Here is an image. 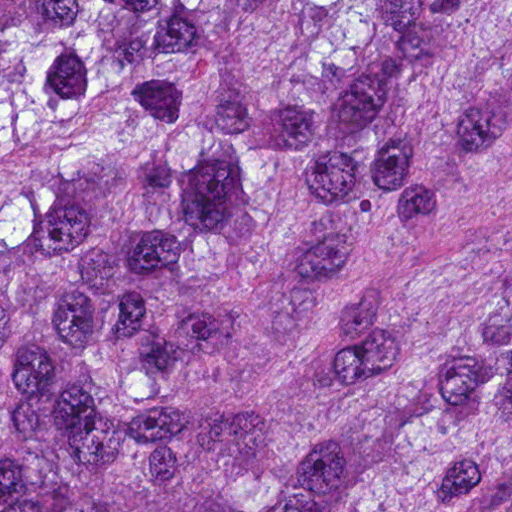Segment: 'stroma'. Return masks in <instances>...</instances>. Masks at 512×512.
<instances>
[{
	"instance_id": "1",
	"label": "stroma",
	"mask_w": 512,
	"mask_h": 512,
	"mask_svg": "<svg viewBox=\"0 0 512 512\" xmlns=\"http://www.w3.org/2000/svg\"><path fill=\"white\" fill-rule=\"evenodd\" d=\"M425 254L438 267H484L512 255V102L477 178Z\"/></svg>"
}]
</instances>
